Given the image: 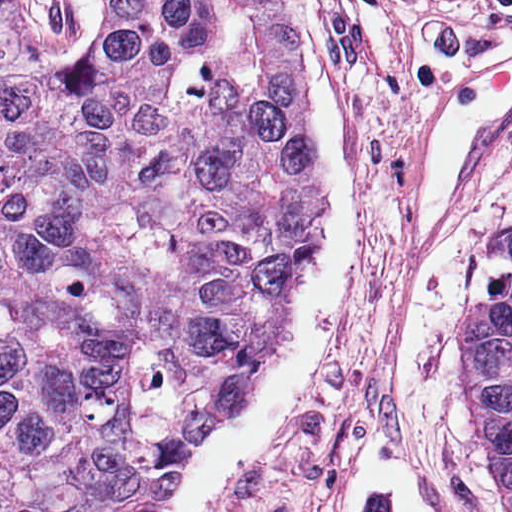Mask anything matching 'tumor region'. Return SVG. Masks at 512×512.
I'll list each match as a JSON object with an SVG mask.
<instances>
[{
	"label": "tumor region",
	"mask_w": 512,
	"mask_h": 512,
	"mask_svg": "<svg viewBox=\"0 0 512 512\" xmlns=\"http://www.w3.org/2000/svg\"><path fill=\"white\" fill-rule=\"evenodd\" d=\"M307 121L271 0H111L80 64L0 0V512L163 502L277 335L317 219ZM469 331L512 497V272Z\"/></svg>",
	"instance_id": "tumor-region-1"
}]
</instances>
